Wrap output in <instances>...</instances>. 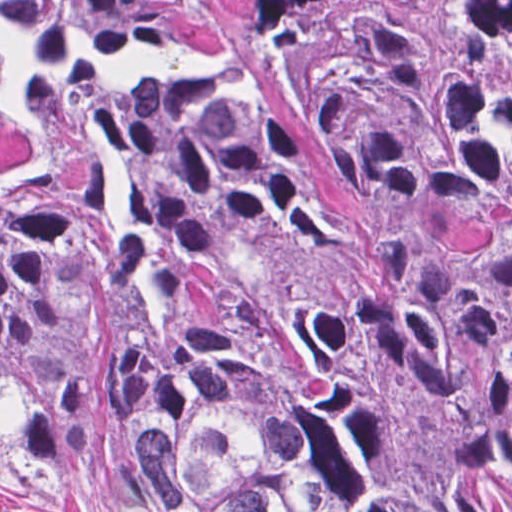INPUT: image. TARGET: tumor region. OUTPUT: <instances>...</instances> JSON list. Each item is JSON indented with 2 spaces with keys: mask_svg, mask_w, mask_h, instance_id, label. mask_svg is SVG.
Segmentation results:
<instances>
[{
  "mask_svg": "<svg viewBox=\"0 0 512 512\" xmlns=\"http://www.w3.org/2000/svg\"><path fill=\"white\" fill-rule=\"evenodd\" d=\"M0 448L90 512H512V0H0Z\"/></svg>",
  "mask_w": 512,
  "mask_h": 512,
  "instance_id": "1",
  "label": "tumor region"
}]
</instances>
